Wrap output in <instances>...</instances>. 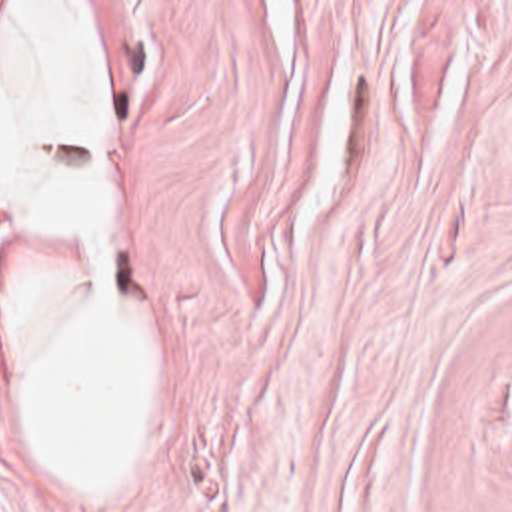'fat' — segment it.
<instances>
[{
	"label": "fat",
	"instance_id": "fat-1",
	"mask_svg": "<svg viewBox=\"0 0 512 512\" xmlns=\"http://www.w3.org/2000/svg\"><path fill=\"white\" fill-rule=\"evenodd\" d=\"M101 121L103 83L73 3L23 1L0 37V209L87 265L23 301L15 381L39 460L75 498L129 486L155 395V331L113 293Z\"/></svg>",
	"mask_w": 512,
	"mask_h": 512
}]
</instances>
